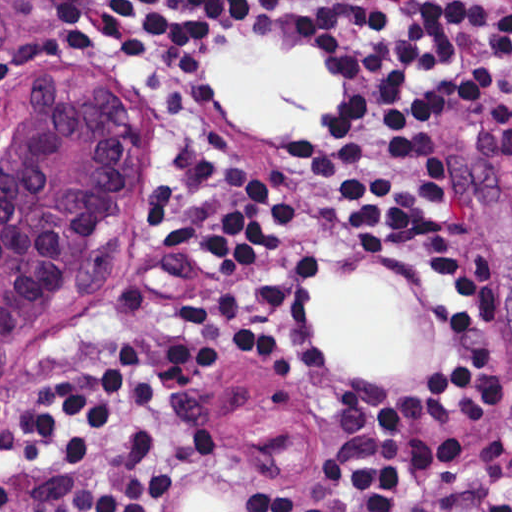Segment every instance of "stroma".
<instances>
[{
    "instance_id": "stroma-1",
    "label": "stroma",
    "mask_w": 512,
    "mask_h": 512,
    "mask_svg": "<svg viewBox=\"0 0 512 512\" xmlns=\"http://www.w3.org/2000/svg\"><path fill=\"white\" fill-rule=\"evenodd\" d=\"M345 14L324 0H289L265 28L224 42H277L309 51V33ZM152 64L84 47L29 0H0V145L21 105L62 83L93 87L117 108L128 162L100 210L71 282L30 327L0 342V418L46 389L76 349L123 318L152 277V231L176 168L209 153L244 157L279 193L298 239L320 261L312 312L328 341L323 376L289 388L258 364L214 357L204 394L218 419L219 446L178 494V512H234L276 503L300 482L323 424L354 399L435 371L444 354L422 292L401 270L346 228L305 210L296 192L298 142L307 129H256L227 109L203 65L207 46ZM78 86V85H77ZM437 164L462 211L460 257L490 254L497 313L475 336L504 377V417L512 427V174L471 109L439 118ZM377 292L410 315V345L395 371H358L322 325L323 292Z\"/></svg>"
}]
</instances>
